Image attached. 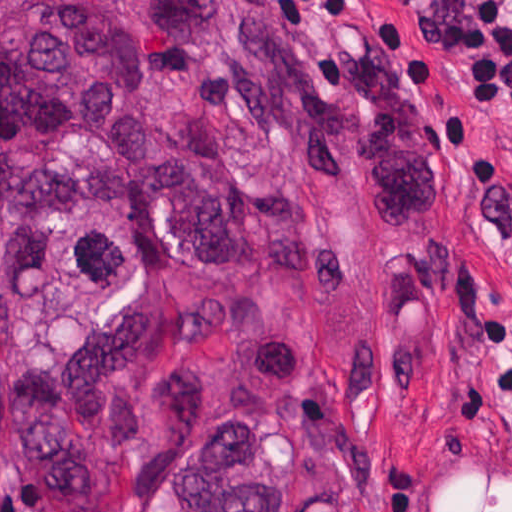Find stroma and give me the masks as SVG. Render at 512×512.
Masks as SVG:
<instances>
[{"label":"stroma","instance_id":"obj_1","mask_svg":"<svg viewBox=\"0 0 512 512\" xmlns=\"http://www.w3.org/2000/svg\"><path fill=\"white\" fill-rule=\"evenodd\" d=\"M314 72L393 47L432 108L434 201L387 236L379 366L384 484L397 512H512V127L471 103L454 0H275ZM123 512H186L151 475L166 458L110 432ZM0 512H47L0 464ZM199 512V511H198Z\"/></svg>","mask_w":512,"mask_h":512}]
</instances>
